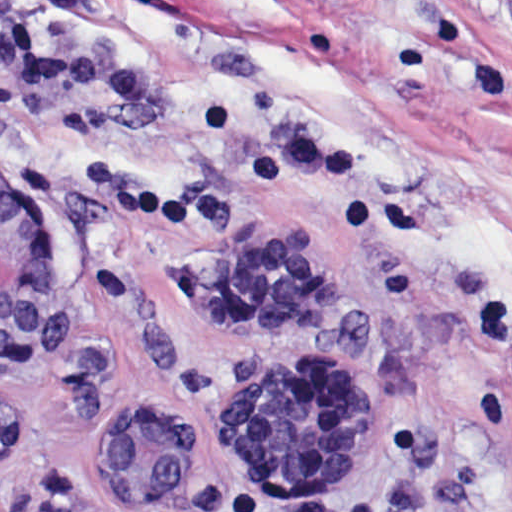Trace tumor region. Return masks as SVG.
<instances>
[{
	"instance_id": "1",
	"label": "tumor region",
	"mask_w": 512,
	"mask_h": 512,
	"mask_svg": "<svg viewBox=\"0 0 512 512\" xmlns=\"http://www.w3.org/2000/svg\"><path fill=\"white\" fill-rule=\"evenodd\" d=\"M228 387L274 494L264 506L307 505L350 484L370 465V444L358 436L344 378L301 365L258 363L236 372ZM25 434L22 410L0 403V458ZM89 441L102 463L158 508L224 507L201 492L198 454L170 414L119 408L98 416Z\"/></svg>"
}]
</instances>
